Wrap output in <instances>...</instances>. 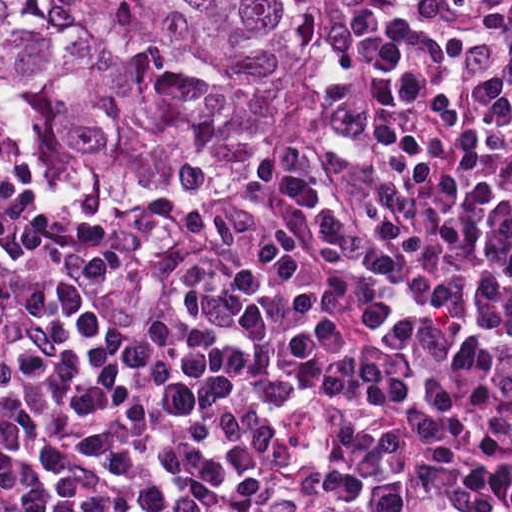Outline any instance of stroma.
<instances>
[{"label": "stroma", "mask_w": 512, "mask_h": 512, "mask_svg": "<svg viewBox=\"0 0 512 512\" xmlns=\"http://www.w3.org/2000/svg\"><path fill=\"white\" fill-rule=\"evenodd\" d=\"M352 5L353 0H334V12L310 56L299 80L296 95L286 112L283 142L277 157L271 165L257 170L238 187L224 191H206L186 205L154 197H120L94 207L49 206L29 186L16 158L11 132H0V176L11 204L23 211H99L128 208L138 216L154 218L229 216L254 206L277 185L292 159L297 132L318 91L321 77L339 48Z\"/></svg>", "instance_id": "obj_1"}]
</instances>
